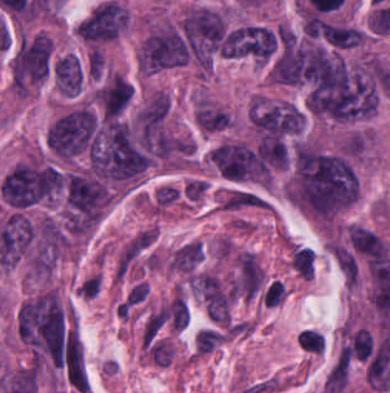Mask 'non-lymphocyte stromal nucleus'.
<instances>
[{
	"label": "non-lymphocyte stromal nucleus",
	"instance_id": "non-lymphocyte-stromal-nucleus-1",
	"mask_svg": "<svg viewBox=\"0 0 390 393\" xmlns=\"http://www.w3.org/2000/svg\"><path fill=\"white\" fill-rule=\"evenodd\" d=\"M195 290L211 318L218 322H229L232 300L228 284L211 272H197Z\"/></svg>",
	"mask_w": 390,
	"mask_h": 393
},
{
	"label": "non-lymphocyte stromal nucleus",
	"instance_id": "non-lymphocyte-stromal-nucleus-2",
	"mask_svg": "<svg viewBox=\"0 0 390 393\" xmlns=\"http://www.w3.org/2000/svg\"><path fill=\"white\" fill-rule=\"evenodd\" d=\"M204 255V249L196 241L185 242L168 261L170 270L180 272L196 271Z\"/></svg>",
	"mask_w": 390,
	"mask_h": 393
},
{
	"label": "non-lymphocyte stromal nucleus",
	"instance_id": "non-lymphocyte-stromal-nucleus-3",
	"mask_svg": "<svg viewBox=\"0 0 390 393\" xmlns=\"http://www.w3.org/2000/svg\"><path fill=\"white\" fill-rule=\"evenodd\" d=\"M169 318V306H161L147 315L143 324L142 342L153 347Z\"/></svg>",
	"mask_w": 390,
	"mask_h": 393
}]
</instances>
